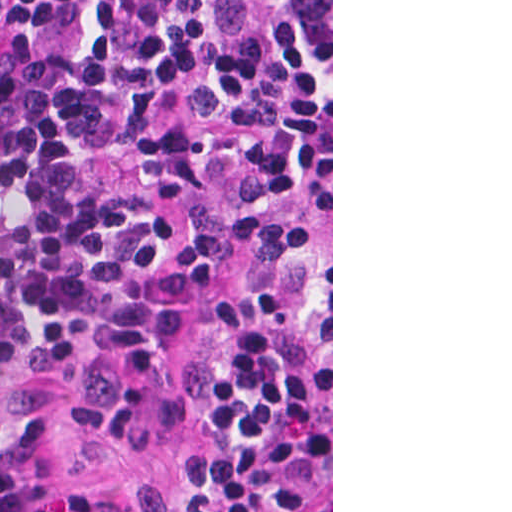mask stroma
Masks as SVG:
<instances>
[{
    "label": "stroma",
    "instance_id": "obj_1",
    "mask_svg": "<svg viewBox=\"0 0 512 512\" xmlns=\"http://www.w3.org/2000/svg\"><path fill=\"white\" fill-rule=\"evenodd\" d=\"M331 455L292 512H333V0H331ZM200 426L44 424L0 430L27 479L0 512L82 506L158 512L177 489Z\"/></svg>",
    "mask_w": 512,
    "mask_h": 512
}]
</instances>
